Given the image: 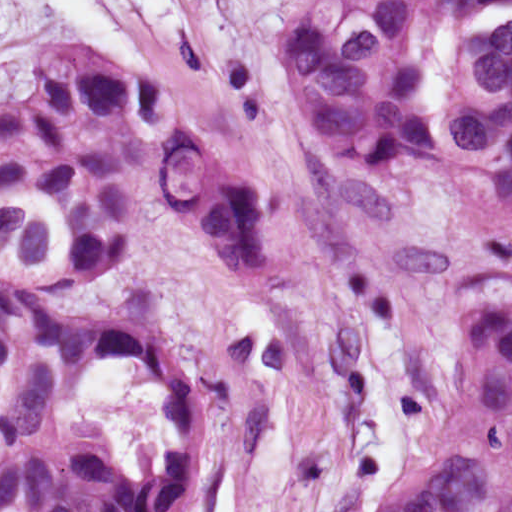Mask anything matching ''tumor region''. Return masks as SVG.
<instances>
[{
    "mask_svg": "<svg viewBox=\"0 0 512 512\" xmlns=\"http://www.w3.org/2000/svg\"><path fill=\"white\" fill-rule=\"evenodd\" d=\"M9 0H0V31ZM311 125L353 168L432 172L512 223V0H283ZM179 204L255 276L273 233L197 96L91 29L0 92V512H168L200 460L171 327L98 270ZM458 285L424 428L369 512H512V268Z\"/></svg>",
    "mask_w": 512,
    "mask_h": 512,
    "instance_id": "e687c5a6",
    "label": "tumor region"
}]
</instances>
